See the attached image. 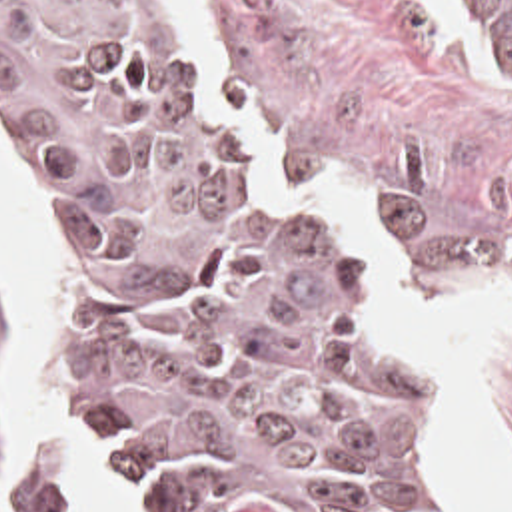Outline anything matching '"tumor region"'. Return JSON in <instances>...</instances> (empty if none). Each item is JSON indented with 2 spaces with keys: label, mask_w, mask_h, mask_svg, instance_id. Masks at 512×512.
Here are the masks:
<instances>
[{
  "label": "tumor region",
  "mask_w": 512,
  "mask_h": 512,
  "mask_svg": "<svg viewBox=\"0 0 512 512\" xmlns=\"http://www.w3.org/2000/svg\"><path fill=\"white\" fill-rule=\"evenodd\" d=\"M0 135L58 223L62 394L120 512H470L390 293L178 1L0 0Z\"/></svg>",
  "instance_id": "1"
}]
</instances>
